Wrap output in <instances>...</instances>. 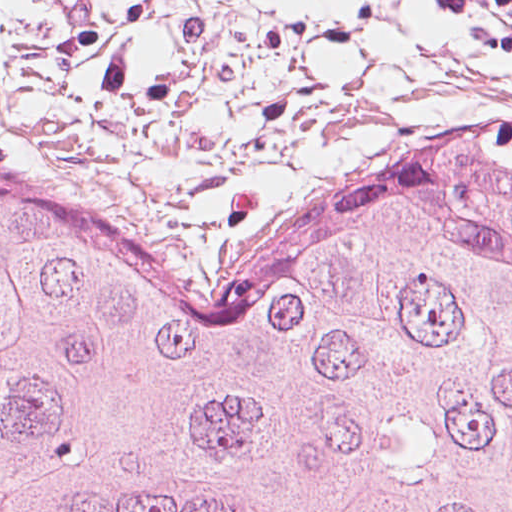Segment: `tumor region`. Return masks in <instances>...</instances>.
I'll list each match as a JSON object with an SVG mask.
<instances>
[{
    "label": "tumor region",
    "instance_id": "obj_1",
    "mask_svg": "<svg viewBox=\"0 0 512 512\" xmlns=\"http://www.w3.org/2000/svg\"><path fill=\"white\" fill-rule=\"evenodd\" d=\"M0 512H512V246L343 211L231 279L0 171Z\"/></svg>",
    "mask_w": 512,
    "mask_h": 512
}]
</instances>
